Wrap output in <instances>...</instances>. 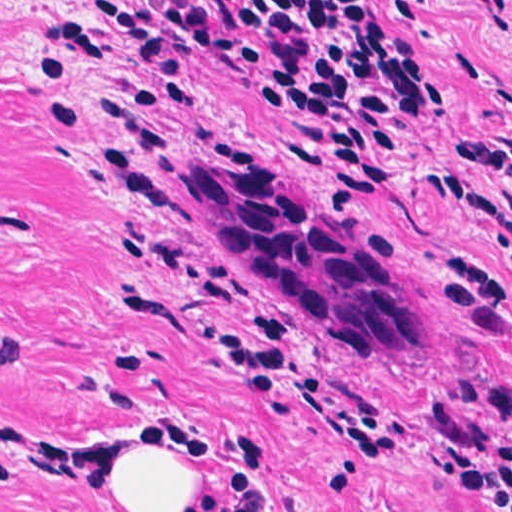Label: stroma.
Segmentation results:
<instances>
[{
    "instance_id": "stroma-1",
    "label": "stroma",
    "mask_w": 512,
    "mask_h": 512,
    "mask_svg": "<svg viewBox=\"0 0 512 512\" xmlns=\"http://www.w3.org/2000/svg\"><path fill=\"white\" fill-rule=\"evenodd\" d=\"M99 0H0V512H105L94 482L125 441L203 444L195 512H452L433 468L512 435V337L476 333L440 294L446 260L505 239L441 175L503 179L455 144L512 147V29L467 0H366L394 17L433 80L399 130L379 195L284 165L294 117L249 101L219 60H192L199 126L127 113V52ZM143 2L147 0H129ZM75 16L101 61L43 41ZM33 54L72 70L38 93ZM87 122L68 150L47 109ZM251 151L342 239L397 246L418 349L351 355L288 308L211 232L188 175ZM256 309L300 324V375L221 345Z\"/></svg>"
}]
</instances>
